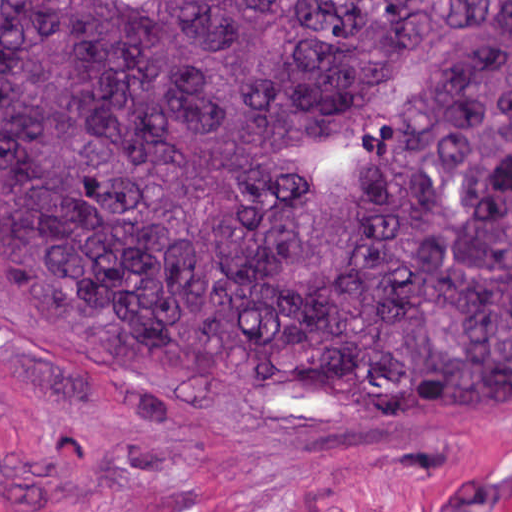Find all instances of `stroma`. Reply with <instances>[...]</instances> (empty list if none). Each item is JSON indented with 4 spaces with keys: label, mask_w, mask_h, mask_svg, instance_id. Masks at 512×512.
Here are the masks:
<instances>
[{
    "label": "stroma",
    "mask_w": 512,
    "mask_h": 512,
    "mask_svg": "<svg viewBox=\"0 0 512 512\" xmlns=\"http://www.w3.org/2000/svg\"><path fill=\"white\" fill-rule=\"evenodd\" d=\"M0 512H512V417L122 353L0 289Z\"/></svg>",
    "instance_id": "obj_1"
}]
</instances>
